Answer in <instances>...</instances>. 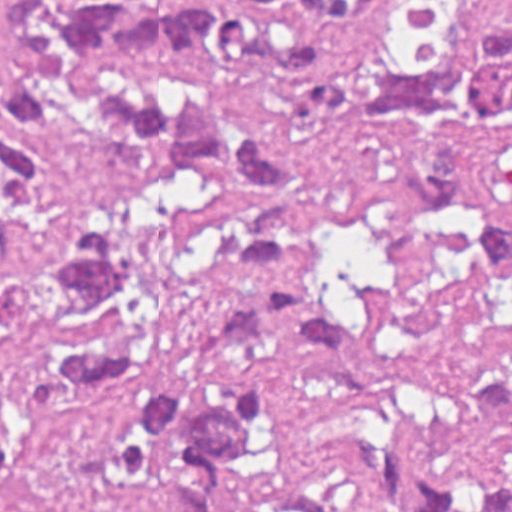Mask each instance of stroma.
I'll return each instance as SVG.
<instances>
[{
  "label": "stroma",
  "mask_w": 512,
  "mask_h": 512,
  "mask_svg": "<svg viewBox=\"0 0 512 512\" xmlns=\"http://www.w3.org/2000/svg\"><path fill=\"white\" fill-rule=\"evenodd\" d=\"M185 1L302 34L308 55L299 67L246 93L242 110L283 158L281 177L167 179L140 202L153 351L118 391L59 407L44 396L27 340L0 350V512H166L160 468L148 483L114 474L135 392L156 382L204 398L228 375L264 382V417L244 460L212 473L220 512H263L291 495H312L326 512H409L411 502H368L338 453L347 378L333 359L292 344L202 352L190 325L239 277L241 227L291 203L361 313L409 424L434 422L485 379L512 377V271L485 261L432 199L406 195L394 177L395 137L315 126L297 110L308 68L363 49H450L482 13H503L512 25V0H385L361 26L294 0ZM471 180L512 225V133L489 142ZM386 189L394 196L377 193ZM426 473L445 476L464 502L490 482L512 495V429L474 426L429 443Z\"/></svg>",
  "instance_id": "1"
}]
</instances>
